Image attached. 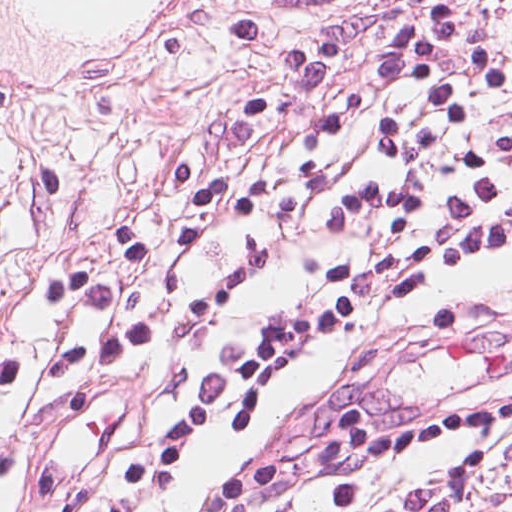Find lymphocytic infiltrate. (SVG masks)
Listing matches in <instances>:
<instances>
[{"mask_svg":"<svg viewBox=\"0 0 512 512\" xmlns=\"http://www.w3.org/2000/svg\"><path fill=\"white\" fill-rule=\"evenodd\" d=\"M329 18L252 89L171 182L172 220H122L43 284L76 325L47 374L33 512H167L209 432L222 449L198 512H407L389 453L450 440L440 483L474 497L512 436V0H393L371 77L322 132L355 131L382 96L357 179L310 168L287 210L309 271L233 335L234 287L210 280L189 329L185 392L142 400L104 446L52 440L79 385L129 365L164 327L182 272L271 193L273 167L322 91ZM19 358L0 349V505L19 439Z\"/></svg>","mask_w":512,"mask_h":512,"instance_id":"obj_1","label":"lymphocytic infiltrate"}]
</instances>
